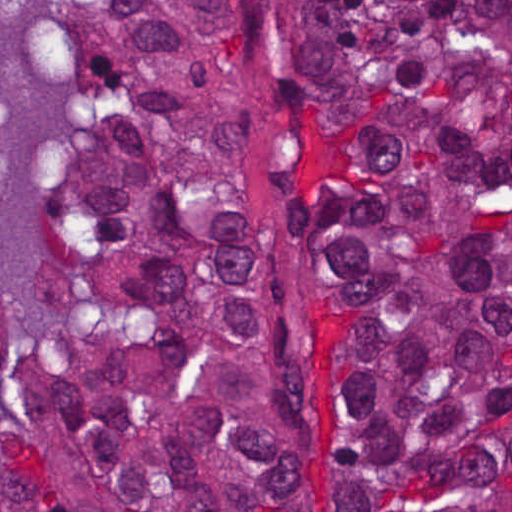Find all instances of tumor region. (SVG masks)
<instances>
[{"mask_svg": "<svg viewBox=\"0 0 512 512\" xmlns=\"http://www.w3.org/2000/svg\"><path fill=\"white\" fill-rule=\"evenodd\" d=\"M46 17L80 137L27 336L0 280V512H512V1Z\"/></svg>", "mask_w": 512, "mask_h": 512, "instance_id": "tumor-region-1", "label": "tumor region"}]
</instances>
